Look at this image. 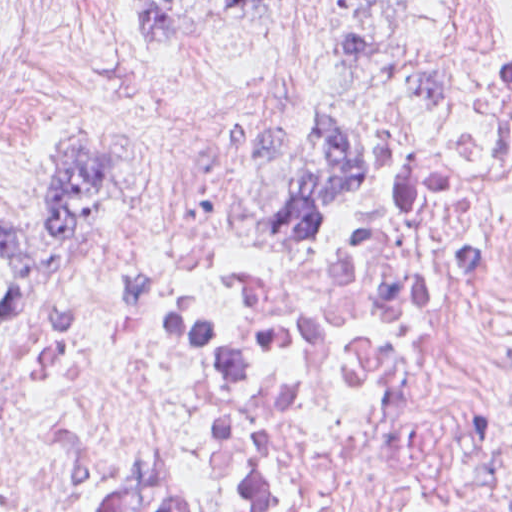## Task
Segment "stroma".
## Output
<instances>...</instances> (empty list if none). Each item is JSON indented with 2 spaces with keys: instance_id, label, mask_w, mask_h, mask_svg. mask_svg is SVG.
I'll return each mask as SVG.
<instances>
[{
  "instance_id": "stroma-1",
  "label": "stroma",
  "mask_w": 512,
  "mask_h": 512,
  "mask_svg": "<svg viewBox=\"0 0 512 512\" xmlns=\"http://www.w3.org/2000/svg\"><path fill=\"white\" fill-rule=\"evenodd\" d=\"M350 2L265 0L153 65L128 0H0V209L49 203L52 162L74 135L108 146L138 181L117 229L76 244L59 282L14 314L0 260V366L76 285L157 249H210L271 288L333 279L359 258L512 61V0H362L372 58L331 64L305 93ZM328 115L355 130L365 173L352 200L326 209L339 240L321 252L268 217L311 182L308 132Z\"/></svg>"
}]
</instances>
